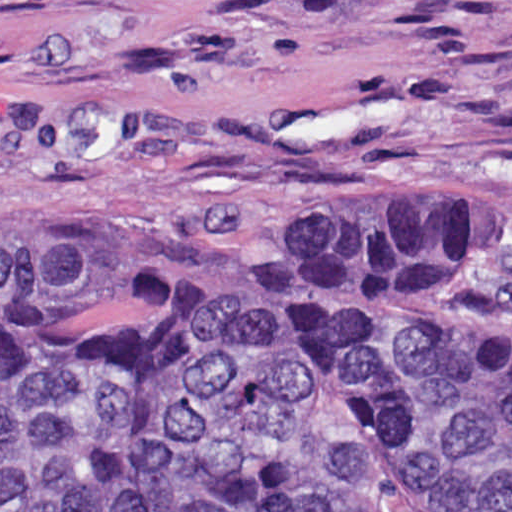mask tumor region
<instances>
[{
	"label": "tumor region",
	"mask_w": 512,
	"mask_h": 512,
	"mask_svg": "<svg viewBox=\"0 0 512 512\" xmlns=\"http://www.w3.org/2000/svg\"><path fill=\"white\" fill-rule=\"evenodd\" d=\"M503 214L272 212L118 264L0 208V512H512V332L458 292Z\"/></svg>",
	"instance_id": "1"
}]
</instances>
